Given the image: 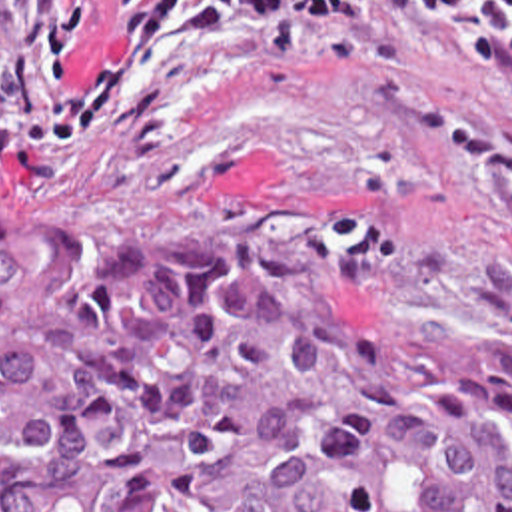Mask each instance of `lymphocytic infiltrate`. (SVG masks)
<instances>
[{"label": "lymphocytic infiltrate", "instance_id": "lymphocytic-infiltrate-1", "mask_svg": "<svg viewBox=\"0 0 512 512\" xmlns=\"http://www.w3.org/2000/svg\"><path fill=\"white\" fill-rule=\"evenodd\" d=\"M113 32L93 80L69 110L47 118L25 136L29 142H91L127 90L155 60L173 28L177 38H205L233 28L261 46L269 66L281 64L299 44L303 18L352 10L350 0H111ZM101 0H65L53 22V50L65 72L69 48L87 32ZM179 14V16H177Z\"/></svg>", "mask_w": 512, "mask_h": 512}]
</instances>
